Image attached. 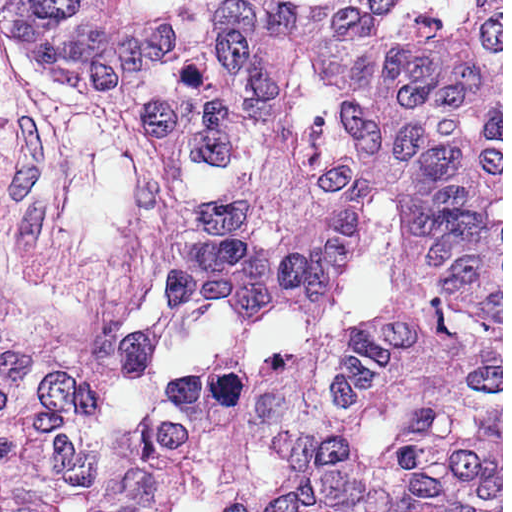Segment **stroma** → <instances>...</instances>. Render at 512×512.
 <instances>
[{
    "label": "stroma",
    "mask_w": 512,
    "mask_h": 512,
    "mask_svg": "<svg viewBox=\"0 0 512 512\" xmlns=\"http://www.w3.org/2000/svg\"><path fill=\"white\" fill-rule=\"evenodd\" d=\"M255 164L217 167L0 29V504L147 438L173 379L242 375L380 323L402 285L385 211L332 320L251 324L177 301L161 269L169 205L234 197Z\"/></svg>",
    "instance_id": "35a3bbf8"
}]
</instances>
